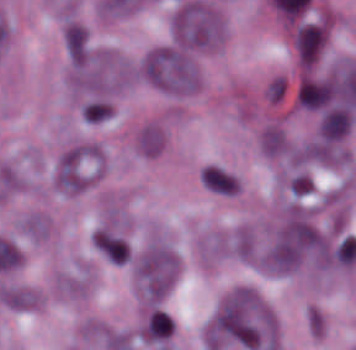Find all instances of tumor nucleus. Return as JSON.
Segmentation results:
<instances>
[{"label": "tumor nucleus", "instance_id": "8643909e", "mask_svg": "<svg viewBox=\"0 0 356 350\" xmlns=\"http://www.w3.org/2000/svg\"><path fill=\"white\" fill-rule=\"evenodd\" d=\"M142 75L156 87L173 93H191L200 87L199 70L189 50L174 44H161L147 52Z\"/></svg>", "mask_w": 356, "mask_h": 350}, {"label": "tumor nucleus", "instance_id": "962dda3e", "mask_svg": "<svg viewBox=\"0 0 356 350\" xmlns=\"http://www.w3.org/2000/svg\"><path fill=\"white\" fill-rule=\"evenodd\" d=\"M137 144L144 154H157L163 144V136L156 126L148 124L137 136Z\"/></svg>", "mask_w": 356, "mask_h": 350}, {"label": "tumor nucleus", "instance_id": "f7901128", "mask_svg": "<svg viewBox=\"0 0 356 350\" xmlns=\"http://www.w3.org/2000/svg\"><path fill=\"white\" fill-rule=\"evenodd\" d=\"M352 124L346 105L327 108L320 122V133L327 140H336L346 134Z\"/></svg>", "mask_w": 356, "mask_h": 350}, {"label": "tumor nucleus", "instance_id": "c2bd9aea", "mask_svg": "<svg viewBox=\"0 0 356 350\" xmlns=\"http://www.w3.org/2000/svg\"><path fill=\"white\" fill-rule=\"evenodd\" d=\"M92 243L93 248L113 264H126L130 256L129 243L110 226L98 228Z\"/></svg>", "mask_w": 356, "mask_h": 350}, {"label": "tumor nucleus", "instance_id": "2083b535", "mask_svg": "<svg viewBox=\"0 0 356 350\" xmlns=\"http://www.w3.org/2000/svg\"><path fill=\"white\" fill-rule=\"evenodd\" d=\"M293 39L300 65L309 68L325 47L327 28L324 22L303 21L295 28Z\"/></svg>", "mask_w": 356, "mask_h": 350}, {"label": "tumor nucleus", "instance_id": "2f306a5c", "mask_svg": "<svg viewBox=\"0 0 356 350\" xmlns=\"http://www.w3.org/2000/svg\"><path fill=\"white\" fill-rule=\"evenodd\" d=\"M211 337L275 350L278 326L275 314L253 288L221 301L209 322Z\"/></svg>", "mask_w": 356, "mask_h": 350}, {"label": "tumor nucleus", "instance_id": "3d1891a8", "mask_svg": "<svg viewBox=\"0 0 356 350\" xmlns=\"http://www.w3.org/2000/svg\"><path fill=\"white\" fill-rule=\"evenodd\" d=\"M99 144L82 142L65 150L55 169V183L62 191L80 192L92 183L100 169Z\"/></svg>", "mask_w": 356, "mask_h": 350}, {"label": "tumor nucleus", "instance_id": "2cbd58db", "mask_svg": "<svg viewBox=\"0 0 356 350\" xmlns=\"http://www.w3.org/2000/svg\"><path fill=\"white\" fill-rule=\"evenodd\" d=\"M179 264L180 259L174 250L159 241H152L132 254L139 288L145 293H167Z\"/></svg>", "mask_w": 356, "mask_h": 350}, {"label": "tumor nucleus", "instance_id": "80c4ae96", "mask_svg": "<svg viewBox=\"0 0 356 350\" xmlns=\"http://www.w3.org/2000/svg\"><path fill=\"white\" fill-rule=\"evenodd\" d=\"M287 79L282 73L275 72L266 82L263 96L266 102L279 104L284 100L287 90Z\"/></svg>", "mask_w": 356, "mask_h": 350}, {"label": "tumor nucleus", "instance_id": "5ab6c2c4", "mask_svg": "<svg viewBox=\"0 0 356 350\" xmlns=\"http://www.w3.org/2000/svg\"><path fill=\"white\" fill-rule=\"evenodd\" d=\"M171 29L174 43L184 48L212 49L225 35L217 10L195 0H182L177 5Z\"/></svg>", "mask_w": 356, "mask_h": 350}, {"label": "tumor nucleus", "instance_id": "8087334f", "mask_svg": "<svg viewBox=\"0 0 356 350\" xmlns=\"http://www.w3.org/2000/svg\"><path fill=\"white\" fill-rule=\"evenodd\" d=\"M256 144L263 158L282 159L291 142L285 127L277 120H269L260 127Z\"/></svg>", "mask_w": 356, "mask_h": 350}, {"label": "tumor nucleus", "instance_id": "3e47fb67", "mask_svg": "<svg viewBox=\"0 0 356 350\" xmlns=\"http://www.w3.org/2000/svg\"><path fill=\"white\" fill-rule=\"evenodd\" d=\"M173 332V321L169 313L152 310L144 321L141 335L151 344L166 345Z\"/></svg>", "mask_w": 356, "mask_h": 350}, {"label": "tumor nucleus", "instance_id": "268c6acd", "mask_svg": "<svg viewBox=\"0 0 356 350\" xmlns=\"http://www.w3.org/2000/svg\"><path fill=\"white\" fill-rule=\"evenodd\" d=\"M202 182L214 192L223 195H232L240 186L237 176L216 165H209L202 171Z\"/></svg>", "mask_w": 356, "mask_h": 350}, {"label": "tumor nucleus", "instance_id": "1edb0cf7", "mask_svg": "<svg viewBox=\"0 0 356 350\" xmlns=\"http://www.w3.org/2000/svg\"><path fill=\"white\" fill-rule=\"evenodd\" d=\"M0 294L2 303L16 309H26L35 301V292L17 286H4Z\"/></svg>", "mask_w": 356, "mask_h": 350}, {"label": "tumor nucleus", "instance_id": "feef74b5", "mask_svg": "<svg viewBox=\"0 0 356 350\" xmlns=\"http://www.w3.org/2000/svg\"><path fill=\"white\" fill-rule=\"evenodd\" d=\"M332 98V81L303 77L299 84L298 101L303 108L316 109Z\"/></svg>", "mask_w": 356, "mask_h": 350}]
</instances>
